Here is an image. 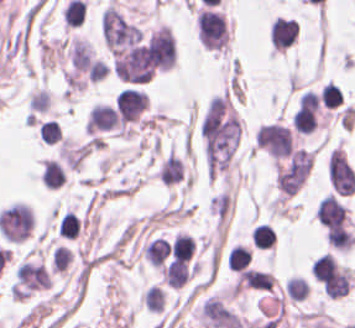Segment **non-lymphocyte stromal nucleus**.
<instances>
[{"instance_id":"dd21d789","label":"non-lymphocyte stromal nucleus","mask_w":355,"mask_h":328,"mask_svg":"<svg viewBox=\"0 0 355 328\" xmlns=\"http://www.w3.org/2000/svg\"><path fill=\"white\" fill-rule=\"evenodd\" d=\"M101 36L112 54H121L141 40L140 29L118 10L107 7L102 14Z\"/></svg>"},{"instance_id":"a72fc3eb","label":"non-lymphocyte stromal nucleus","mask_w":355,"mask_h":328,"mask_svg":"<svg viewBox=\"0 0 355 328\" xmlns=\"http://www.w3.org/2000/svg\"><path fill=\"white\" fill-rule=\"evenodd\" d=\"M328 176L336 194L351 195L355 191V171L340 149L330 154Z\"/></svg>"}]
</instances>
